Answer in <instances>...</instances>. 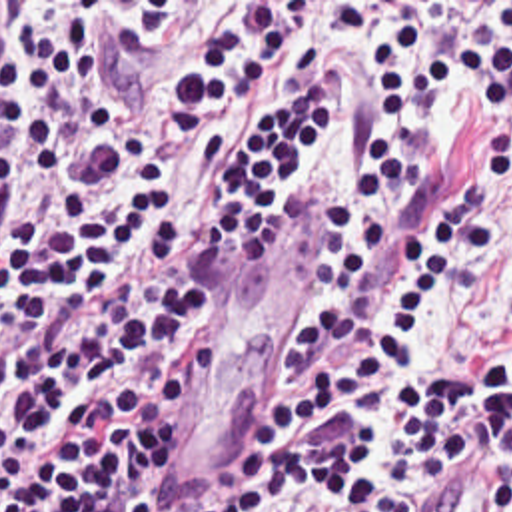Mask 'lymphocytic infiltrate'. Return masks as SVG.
Segmentation results:
<instances>
[{"label": "lymphocytic infiltrate", "mask_w": 512, "mask_h": 512, "mask_svg": "<svg viewBox=\"0 0 512 512\" xmlns=\"http://www.w3.org/2000/svg\"><path fill=\"white\" fill-rule=\"evenodd\" d=\"M304 6L194 22L136 82L84 22L28 24L0 102V512H162L224 367L226 248L274 226L331 138L314 54L194 192L178 158L304 36ZM505 447L512 512V2L411 6L373 52L365 158L333 192L280 373L202 512H435Z\"/></svg>", "instance_id": "obj_1"}]
</instances>
